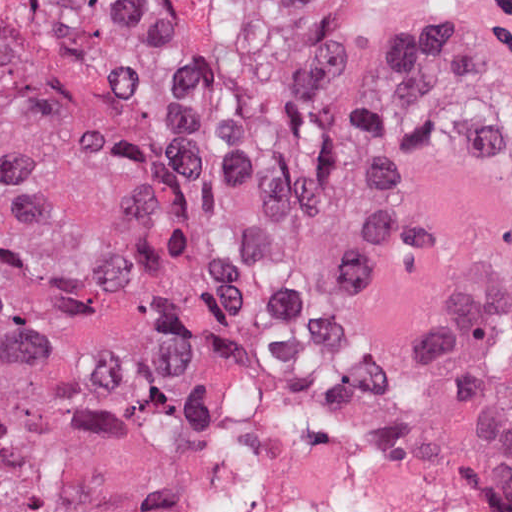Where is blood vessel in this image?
Segmentation results:
<instances>
[{"instance_id":"obj_1","label":"blood vessel","mask_w":512,"mask_h":512,"mask_svg":"<svg viewBox=\"0 0 512 512\" xmlns=\"http://www.w3.org/2000/svg\"><path fill=\"white\" fill-rule=\"evenodd\" d=\"M361 42L397 50L512 47V0H291Z\"/></svg>"}]
</instances>
